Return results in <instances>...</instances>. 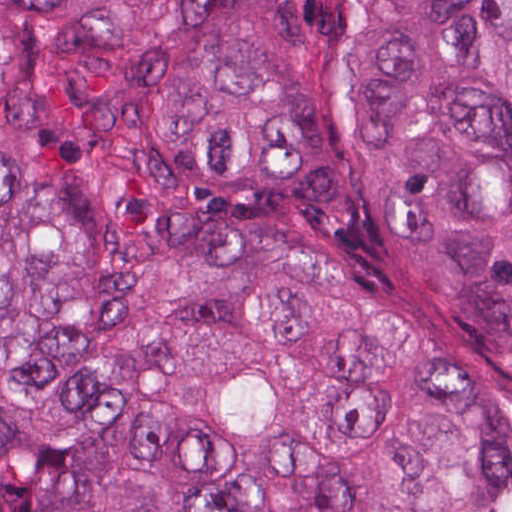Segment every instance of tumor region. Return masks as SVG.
I'll list each match as a JSON object with an SVG mask.
<instances>
[{
	"instance_id": "tumor-region-1",
	"label": "tumor region",
	"mask_w": 512,
	"mask_h": 512,
	"mask_svg": "<svg viewBox=\"0 0 512 512\" xmlns=\"http://www.w3.org/2000/svg\"><path fill=\"white\" fill-rule=\"evenodd\" d=\"M0 512H512V0H0Z\"/></svg>"
}]
</instances>
